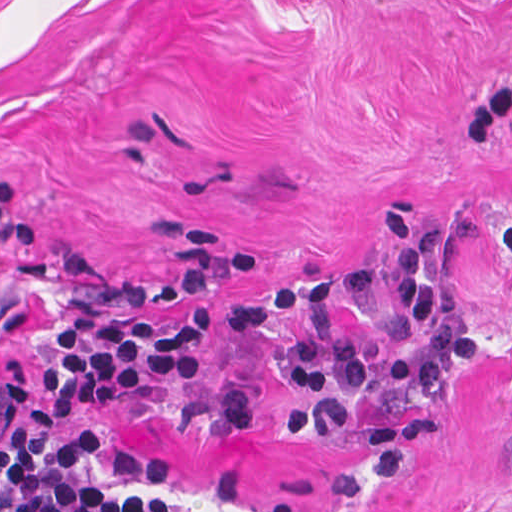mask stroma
<instances>
[{"label":"stroma","mask_w":512,"mask_h":512,"mask_svg":"<svg viewBox=\"0 0 512 512\" xmlns=\"http://www.w3.org/2000/svg\"><path fill=\"white\" fill-rule=\"evenodd\" d=\"M395 211L445 228L459 351L297 439L275 367L305 316L229 313L331 276L350 339L418 341L352 282L394 264ZM213 301L206 368L64 423L97 426V480L195 512H512V0H0V512L62 311Z\"/></svg>","instance_id":"1"}]
</instances>
